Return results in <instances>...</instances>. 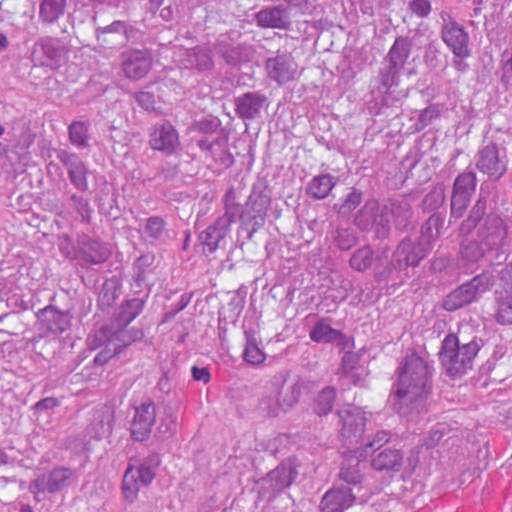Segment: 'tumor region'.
<instances>
[{
    "instance_id": "e687c5a6",
    "label": "tumor region",
    "mask_w": 512,
    "mask_h": 512,
    "mask_svg": "<svg viewBox=\"0 0 512 512\" xmlns=\"http://www.w3.org/2000/svg\"><path fill=\"white\" fill-rule=\"evenodd\" d=\"M471 141L512 0H0V512H512V326L323 227Z\"/></svg>"
}]
</instances>
